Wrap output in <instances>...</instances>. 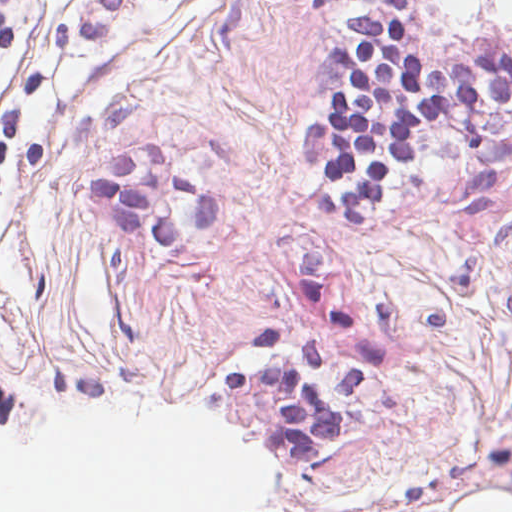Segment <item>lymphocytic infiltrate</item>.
<instances>
[{
  "label": "lymphocytic infiltrate",
  "instance_id": "1",
  "mask_svg": "<svg viewBox=\"0 0 512 512\" xmlns=\"http://www.w3.org/2000/svg\"><path fill=\"white\" fill-rule=\"evenodd\" d=\"M408 22V0H386V12L353 19V40L335 47L337 80L329 85L324 112L299 135V149L323 163L327 192L307 200L323 219H378L434 133L478 112L512 106V50L469 61L421 60L405 42ZM5 45L0 18V54ZM18 131L16 104L0 130V180ZM226 389L278 403L269 428L321 445L335 434L325 393L302 378L238 371Z\"/></svg>",
  "mask_w": 512,
  "mask_h": 512
}]
</instances>
